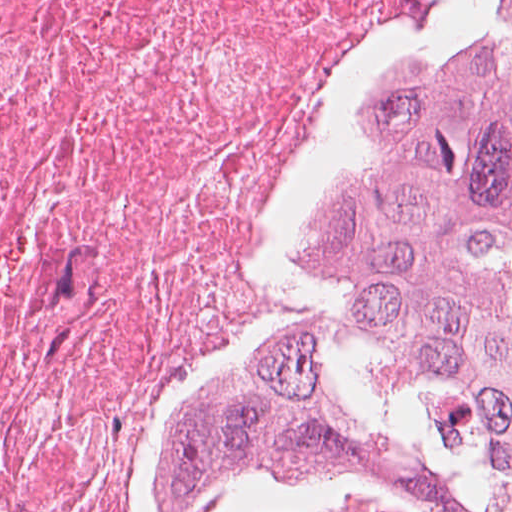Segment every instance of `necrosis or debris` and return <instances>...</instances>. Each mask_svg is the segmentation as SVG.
I'll use <instances>...</instances> for the list:
<instances>
[{"instance_id":"4bbe7bcc","label":"necrosis or debris","mask_w":512,"mask_h":512,"mask_svg":"<svg viewBox=\"0 0 512 512\" xmlns=\"http://www.w3.org/2000/svg\"><path fill=\"white\" fill-rule=\"evenodd\" d=\"M417 2L0 0V512H139L149 445L278 290Z\"/></svg>"}]
</instances>
